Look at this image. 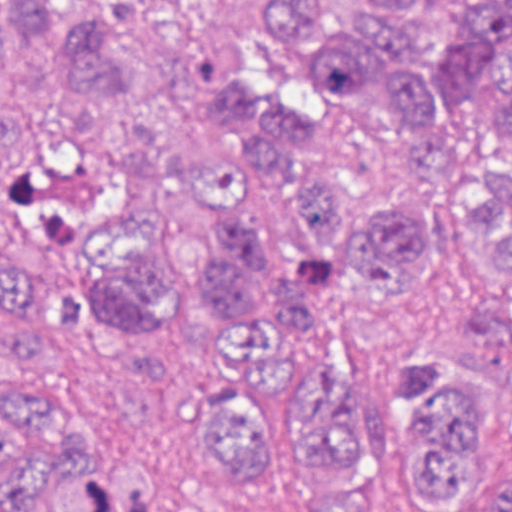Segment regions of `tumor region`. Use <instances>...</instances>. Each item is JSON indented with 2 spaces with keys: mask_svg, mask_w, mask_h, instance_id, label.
<instances>
[{
  "mask_svg": "<svg viewBox=\"0 0 512 512\" xmlns=\"http://www.w3.org/2000/svg\"><path fill=\"white\" fill-rule=\"evenodd\" d=\"M305 72L353 99H389L431 170H461L440 214L359 206L303 152L327 117L251 77L240 39L192 0H18L31 40L67 54L83 93L154 102L251 172L196 166L136 129L118 205L82 251L0 173V367L48 369L67 332L95 363L174 392L204 419V460L235 491L311 468L314 512H383L393 476L424 507L471 512L499 446V396L455 354L412 349L393 427L335 363L279 355L334 279L369 307L418 294L440 256L512 288V0H255ZM18 22L0 2V69ZM499 127L504 163L468 160ZM48 123L0 92V168L36 165ZM150 463L93 442L60 396L0 376V512H157ZM496 512H512V475Z\"/></svg>",
  "mask_w": 512,
  "mask_h": 512,
  "instance_id": "1",
  "label": "tumor region"
}]
</instances>
